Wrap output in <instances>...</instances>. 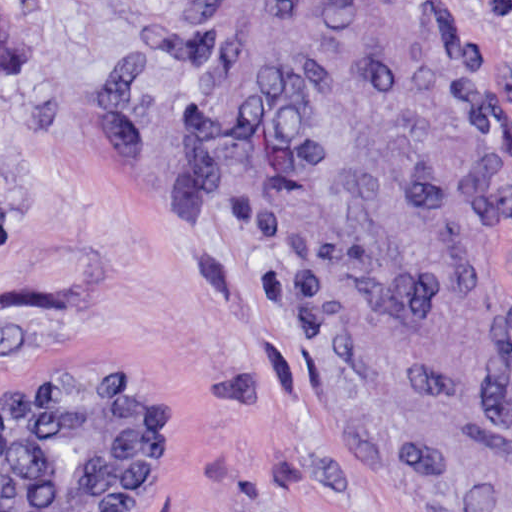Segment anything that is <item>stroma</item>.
Masks as SVG:
<instances>
[{"label": "stroma", "instance_id": "1", "mask_svg": "<svg viewBox=\"0 0 512 512\" xmlns=\"http://www.w3.org/2000/svg\"><path fill=\"white\" fill-rule=\"evenodd\" d=\"M0 24V392L175 403L136 512H512V0Z\"/></svg>", "mask_w": 512, "mask_h": 512}]
</instances>
